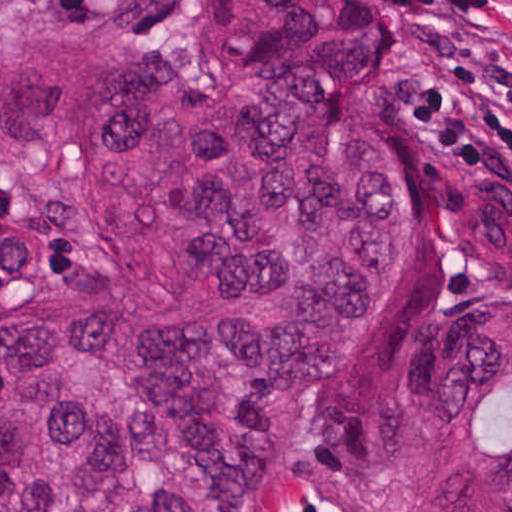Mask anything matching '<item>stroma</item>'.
Segmentation results:
<instances>
[{"label": "stroma", "instance_id": "1", "mask_svg": "<svg viewBox=\"0 0 512 512\" xmlns=\"http://www.w3.org/2000/svg\"><path fill=\"white\" fill-rule=\"evenodd\" d=\"M391 31V49L369 85L372 119L396 154L403 270L395 296L369 312L348 341L357 356L378 370L394 353L440 324L461 296L512 293L489 289L463 275L435 226L433 198L455 178L510 175L491 165H468L411 144L399 127L393 101L418 59L415 35L383 0H368ZM96 16H53L40 0H0V36L71 43L118 52L138 69L153 64L135 50L160 60L176 74L202 86H219L223 72L203 31V0H187L176 26L159 37H131L110 10ZM0 226H40L66 237L31 203L0 183ZM370 479L335 462L311 464L263 499L257 512H353ZM372 495V488L360 512Z\"/></svg>", "mask_w": 512, "mask_h": 512}]
</instances>
